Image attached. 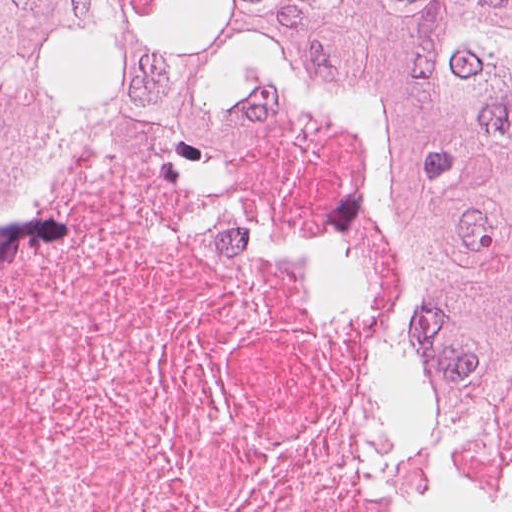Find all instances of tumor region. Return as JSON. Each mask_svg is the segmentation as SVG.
Instances as JSON below:
<instances>
[{
  "mask_svg": "<svg viewBox=\"0 0 512 512\" xmlns=\"http://www.w3.org/2000/svg\"><path fill=\"white\" fill-rule=\"evenodd\" d=\"M85 75L372 115L409 174L419 437L512 503V0H0V158Z\"/></svg>",
  "mask_w": 512,
  "mask_h": 512,
  "instance_id": "e687c5a6",
  "label": "tumor region"
}]
</instances>
